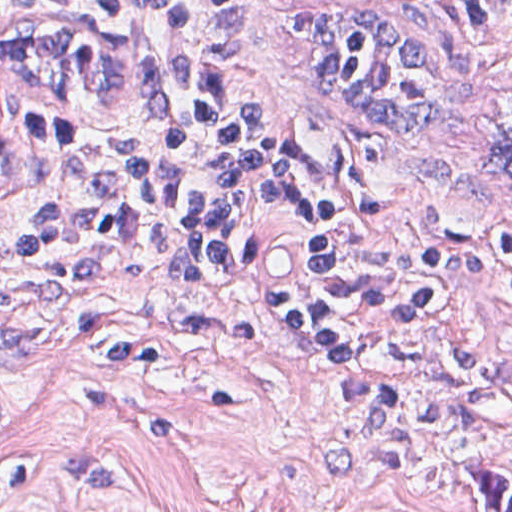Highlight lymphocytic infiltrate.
Wrapping results in <instances>:
<instances>
[{
    "instance_id": "lymphocytic-infiltrate-1",
    "label": "lymphocytic infiltrate",
    "mask_w": 512,
    "mask_h": 512,
    "mask_svg": "<svg viewBox=\"0 0 512 512\" xmlns=\"http://www.w3.org/2000/svg\"><path fill=\"white\" fill-rule=\"evenodd\" d=\"M83 1L155 41L158 126L0 130L2 233L55 252L123 248L180 298L326 362L366 357L446 305L512 318V259L415 225L367 171L306 163L279 125L237 109L230 70L282 0ZM454 1L512 32V0Z\"/></svg>"
}]
</instances>
